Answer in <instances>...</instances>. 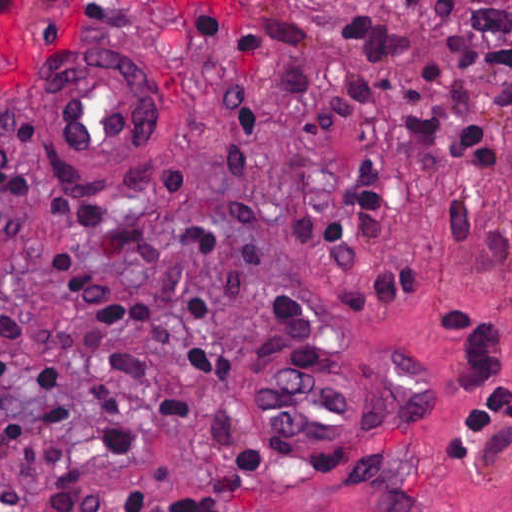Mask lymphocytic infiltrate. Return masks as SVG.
I'll return each mask as SVG.
<instances>
[{"instance_id":"f902f5d3","label":"lymphocytic infiltrate","mask_w":512,"mask_h":512,"mask_svg":"<svg viewBox=\"0 0 512 512\" xmlns=\"http://www.w3.org/2000/svg\"><path fill=\"white\" fill-rule=\"evenodd\" d=\"M403 1L419 6L423 0ZM437 1L436 23L454 65L492 81L493 99L512 132V46L461 30L459 19L470 0ZM336 32L356 78L327 102L317 81L297 72L291 93L308 141L348 136L349 166L331 168L322 176L334 190L328 214H288L280 205L276 221L309 251L335 262H355L384 231L383 161L390 150L426 146L486 169L497 167V150L476 124L449 69L403 26L380 14L343 8L336 15ZM18 196L0 150V229ZM446 225L455 256L471 253L472 212L464 200L450 203ZM176 240L189 253L240 257V229L232 233L214 226H183L176 230ZM473 253L502 266L510 303L504 316L461 308L444 313L438 323L464 346L454 384L467 412L442 433L449 459L483 455L512 419V242L506 233H490ZM47 259L52 289L75 306L74 315L32 307L5 284L0 286V441L39 503L58 512H136L144 506L141 487L86 481V453L71 422L77 410L93 416L98 449L106 460L134 454L132 406L119 382L142 390L156 366L150 357L127 349L122 344L127 338L144 340L179 367L172 387L153 404L155 413L167 420L191 417L197 409L191 380L235 384L234 399L212 410L207 420L223 448L213 474L217 496L240 493L274 464L284 447L238 397V276L226 285L208 286L178 279L164 266L143 265L153 284L149 292L134 293L98 287L68 248L50 250ZM434 275L426 268L391 265L375 280L372 299L404 305ZM276 294L316 330L304 301ZM343 310L344 329L367 320L361 287L345 285ZM165 509L230 512L199 497L169 501ZM0 512H22V501L9 485L0 484Z\"/></svg>"}]
</instances>
